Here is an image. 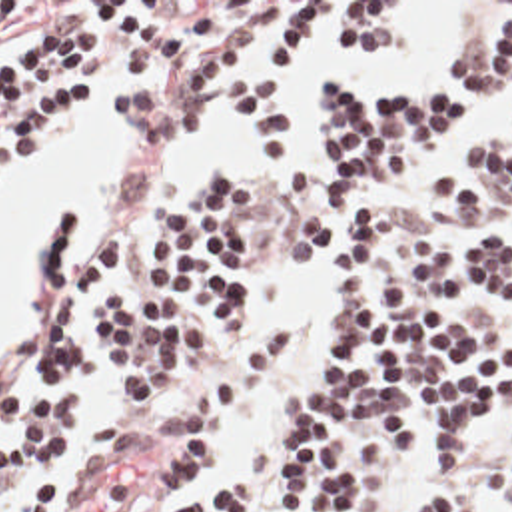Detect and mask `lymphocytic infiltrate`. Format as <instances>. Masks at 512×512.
I'll list each match as a JSON object with an SVG mask.
<instances>
[{
  "label": "lymphocytic infiltrate",
  "mask_w": 512,
  "mask_h": 512,
  "mask_svg": "<svg viewBox=\"0 0 512 512\" xmlns=\"http://www.w3.org/2000/svg\"><path fill=\"white\" fill-rule=\"evenodd\" d=\"M173 2H87L93 16L13 42L17 2H0V186L9 168L71 120L95 112L99 86L139 150L183 148L199 118V86L237 50V32L215 30L217 8ZM323 8V50L357 58L400 46L410 34L396 2H297L271 28L263 64L237 100L263 150H285L289 112L281 74ZM512 98V2L462 60L442 74L347 98L321 80L315 96L317 190L287 252L329 256L333 288L321 333L261 435L219 461L177 497L193 471L235 435L291 355L287 329L253 337L251 240L265 218V188L209 164L191 188L157 210L147 262L157 282L105 284L127 250V232L105 226L85 260L75 256L67 206L45 226L33 375L0 385V512H57L67 485L135 435L147 455L169 453L165 512H390L400 471L420 455L454 471L478 429L512 421V329L486 310L512 304V238L490 232L442 246L426 226L390 228L384 186L418 140L482 100ZM432 200L460 232H478L512 208V132L450 140L432 174ZM211 327L239 347L229 365L141 431H105L77 447L81 399L95 365L149 413L161 415L197 383ZM414 512H484L456 475H434ZM500 512H512V483Z\"/></svg>",
  "instance_id": "obj_1"
}]
</instances>
